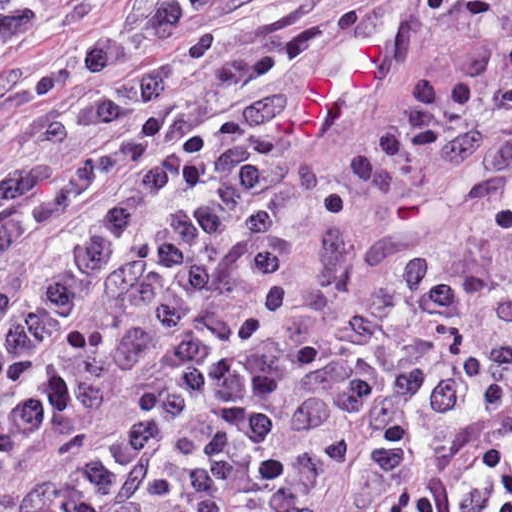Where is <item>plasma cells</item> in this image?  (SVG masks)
Returning a JSON list of instances; mask_svg holds the SVG:
<instances>
[{
  "label": "plasma cells",
  "mask_w": 512,
  "mask_h": 512,
  "mask_svg": "<svg viewBox=\"0 0 512 512\" xmlns=\"http://www.w3.org/2000/svg\"><path fill=\"white\" fill-rule=\"evenodd\" d=\"M287 1L174 0L37 90ZM415 3L477 17L463 67L414 71L336 184L287 158L403 71L413 30L286 95V72L362 27L266 38L322 4L38 125L90 159L0 151V258L120 178L0 282V512H316L346 462L395 486L377 512H512V0ZM57 20L0 0V67Z\"/></svg>",
  "instance_id": "9512152a"
}]
</instances>
